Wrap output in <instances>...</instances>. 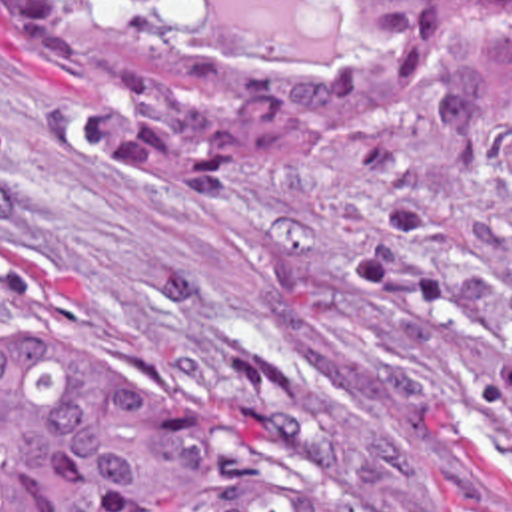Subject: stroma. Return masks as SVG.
Returning a JSON list of instances; mask_svg holds the SVG:
<instances>
[{
    "instance_id": "stroma-1",
    "label": "stroma",
    "mask_w": 512,
    "mask_h": 512,
    "mask_svg": "<svg viewBox=\"0 0 512 512\" xmlns=\"http://www.w3.org/2000/svg\"><path fill=\"white\" fill-rule=\"evenodd\" d=\"M193 50L343 56L353 0H185ZM433 66L293 129L245 193L109 179L77 82L0 20V335L119 347L337 512H512V16L433 0Z\"/></svg>"
}]
</instances>
